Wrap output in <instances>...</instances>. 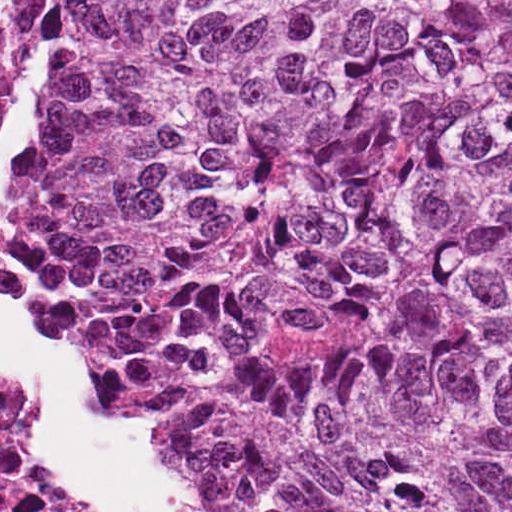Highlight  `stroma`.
<instances>
[{"mask_svg":"<svg viewBox=\"0 0 512 512\" xmlns=\"http://www.w3.org/2000/svg\"><path fill=\"white\" fill-rule=\"evenodd\" d=\"M6 1H512V0H0V387L6 386L1 377V11ZM105 360V359H104ZM105 401L109 411L136 419L131 395L120 368L105 360ZM40 469L62 477L48 462L36 440Z\"/></svg>","mask_w":512,"mask_h":512,"instance_id":"stroma-1","label":"stroma"}]
</instances>
